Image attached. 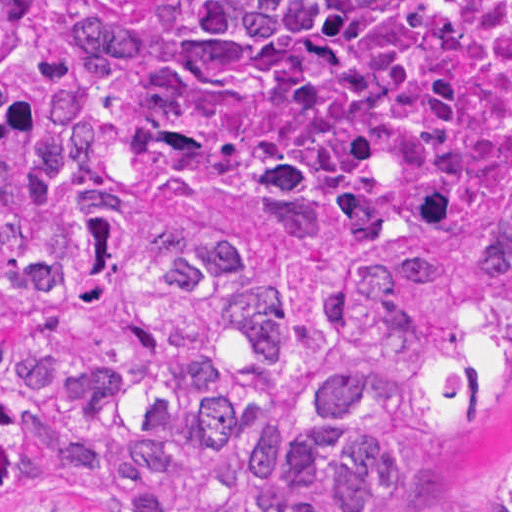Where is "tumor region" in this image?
Segmentation results:
<instances>
[{"label": "tumor region", "instance_id": "obj_1", "mask_svg": "<svg viewBox=\"0 0 512 512\" xmlns=\"http://www.w3.org/2000/svg\"><path fill=\"white\" fill-rule=\"evenodd\" d=\"M511 327L512 0H0V512H390Z\"/></svg>", "mask_w": 512, "mask_h": 512}]
</instances>
